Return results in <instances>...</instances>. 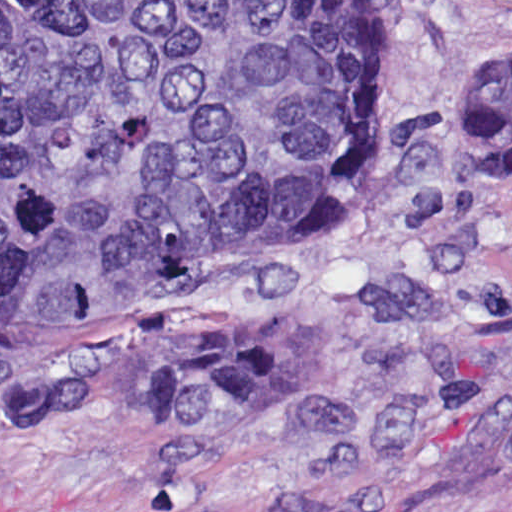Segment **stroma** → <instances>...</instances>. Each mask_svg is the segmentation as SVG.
Listing matches in <instances>:
<instances>
[{"label":"stroma","mask_w":512,"mask_h":512,"mask_svg":"<svg viewBox=\"0 0 512 512\" xmlns=\"http://www.w3.org/2000/svg\"><path fill=\"white\" fill-rule=\"evenodd\" d=\"M394 58L364 171L176 305L307 320L285 402L218 428L19 411L109 329L0 327V512H480L512 503V167L461 141L512 0H374ZM293 312V313H292Z\"/></svg>","instance_id":"obj_1"}]
</instances>
